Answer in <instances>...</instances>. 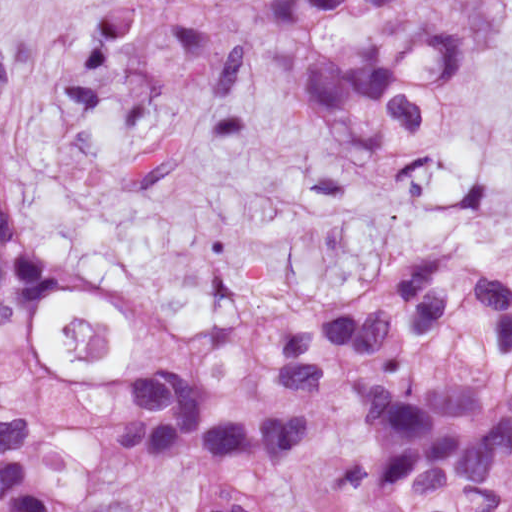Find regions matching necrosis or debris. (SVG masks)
Listing matches in <instances>:
<instances>
[{
	"instance_id": "obj_1",
	"label": "necrosis or debris",
	"mask_w": 512,
	"mask_h": 512,
	"mask_svg": "<svg viewBox=\"0 0 512 512\" xmlns=\"http://www.w3.org/2000/svg\"><path fill=\"white\" fill-rule=\"evenodd\" d=\"M67 359L74 362H101L109 350L110 326L106 319L87 321L68 318L61 326Z\"/></svg>"
}]
</instances>
